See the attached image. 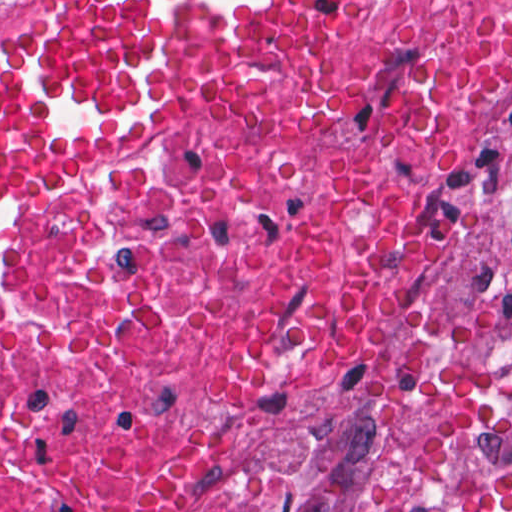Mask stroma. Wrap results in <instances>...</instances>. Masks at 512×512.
Masks as SVG:
<instances>
[{
	"mask_svg": "<svg viewBox=\"0 0 512 512\" xmlns=\"http://www.w3.org/2000/svg\"><path fill=\"white\" fill-rule=\"evenodd\" d=\"M392 1L358 0L339 21L331 38L313 53L296 75L240 103L192 110L133 142L128 152L144 146L124 160L125 154H122L64 164H35L14 174L2 187L58 170L166 153L236 129L295 89L330 50ZM20 15L21 0H0V58ZM474 164L491 180L484 178L491 210V258L495 282L512 329V67L495 108L493 125Z\"/></svg>",
	"mask_w": 512,
	"mask_h": 512,
	"instance_id": "35a3bbf8",
	"label": "stroma"
}]
</instances>
